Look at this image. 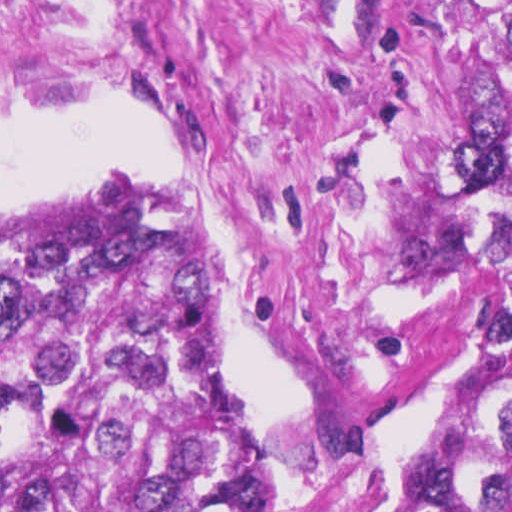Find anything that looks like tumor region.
<instances>
[{"mask_svg": "<svg viewBox=\"0 0 512 512\" xmlns=\"http://www.w3.org/2000/svg\"><path fill=\"white\" fill-rule=\"evenodd\" d=\"M458 419L412 449L419 512H512V21L467 81ZM195 220L59 206L0 228V512H279Z\"/></svg>", "mask_w": 512, "mask_h": 512, "instance_id": "1", "label": "tumor region"}]
</instances>
